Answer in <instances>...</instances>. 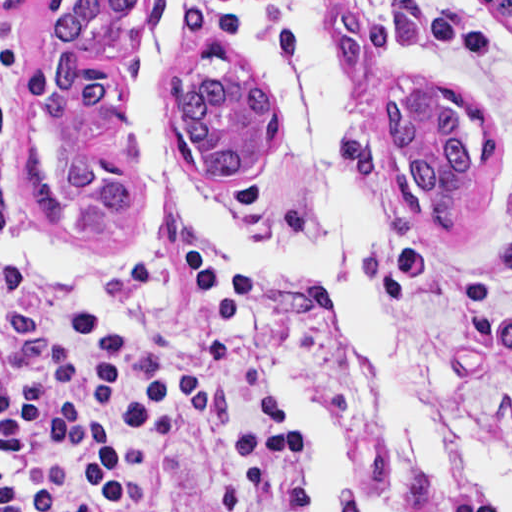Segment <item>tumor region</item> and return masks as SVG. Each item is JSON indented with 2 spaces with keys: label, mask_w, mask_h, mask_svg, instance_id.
Here are the masks:
<instances>
[{
  "label": "tumor region",
  "mask_w": 512,
  "mask_h": 512,
  "mask_svg": "<svg viewBox=\"0 0 512 512\" xmlns=\"http://www.w3.org/2000/svg\"><path fill=\"white\" fill-rule=\"evenodd\" d=\"M512 29V1H488ZM153 1H59L33 29L29 73L45 91V158L59 203L77 229L110 249H137L153 235L152 207L139 194L105 186L76 161L82 142L122 85L103 59L74 57L142 24ZM481 52V32L455 18H429L397 1L391 18L336 11L340 76L366 87L385 61L406 51ZM70 56V57H69ZM200 69L169 80L162 94L173 150L218 180L245 177L277 147L282 113L250 57L224 41L201 46ZM393 143L394 187L432 232H460L498 170V134L470 102L419 77L389 84L381 113Z\"/></svg>",
  "instance_id": "tumor-region-1"
}]
</instances>
